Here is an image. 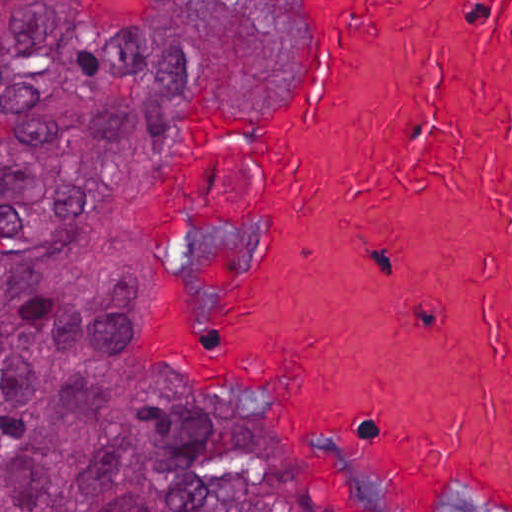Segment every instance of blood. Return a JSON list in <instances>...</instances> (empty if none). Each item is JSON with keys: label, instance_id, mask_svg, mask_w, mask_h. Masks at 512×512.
Listing matches in <instances>:
<instances>
[{"label": "blood", "instance_id": "1", "mask_svg": "<svg viewBox=\"0 0 512 512\" xmlns=\"http://www.w3.org/2000/svg\"><path fill=\"white\" fill-rule=\"evenodd\" d=\"M308 4L301 110L163 150L153 227L269 231L244 315L156 309L165 343L290 388L344 512H512V0Z\"/></svg>", "mask_w": 512, "mask_h": 512}]
</instances>
